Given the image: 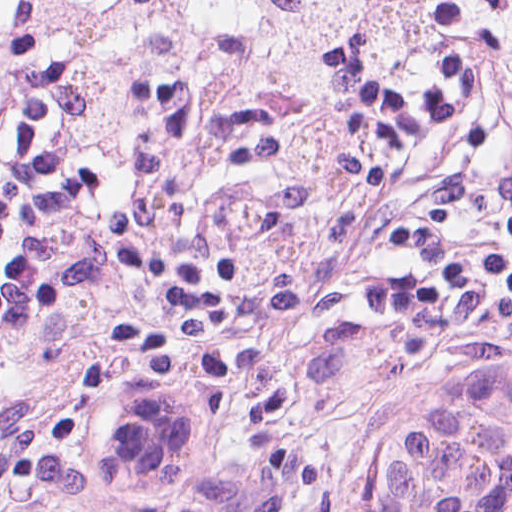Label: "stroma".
I'll use <instances>...</instances> for the list:
<instances>
[{"mask_svg": "<svg viewBox=\"0 0 512 512\" xmlns=\"http://www.w3.org/2000/svg\"><path fill=\"white\" fill-rule=\"evenodd\" d=\"M0 1H48L0 512H71L48 405L110 365H209L239 395L512 61V0Z\"/></svg>", "mask_w": 512, "mask_h": 512, "instance_id": "obj_1", "label": "stroma"}]
</instances>
